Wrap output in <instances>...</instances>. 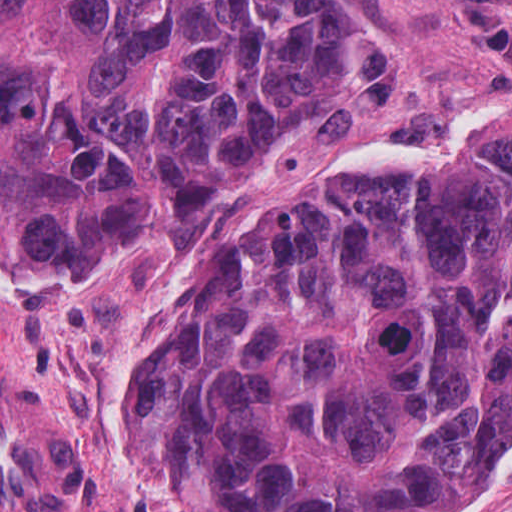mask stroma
Returning <instances> with one entry per match:
<instances>
[{"mask_svg": "<svg viewBox=\"0 0 512 512\" xmlns=\"http://www.w3.org/2000/svg\"><path fill=\"white\" fill-rule=\"evenodd\" d=\"M509 114L512 0H367L340 93L189 245L1 283L0 0V512H198L133 463L110 414L169 333L200 256L243 226L314 205L354 170L442 160ZM453 512H512V437L487 485Z\"/></svg>", "mask_w": 512, "mask_h": 512, "instance_id": "35a3bbf8", "label": "stroma"}]
</instances>
